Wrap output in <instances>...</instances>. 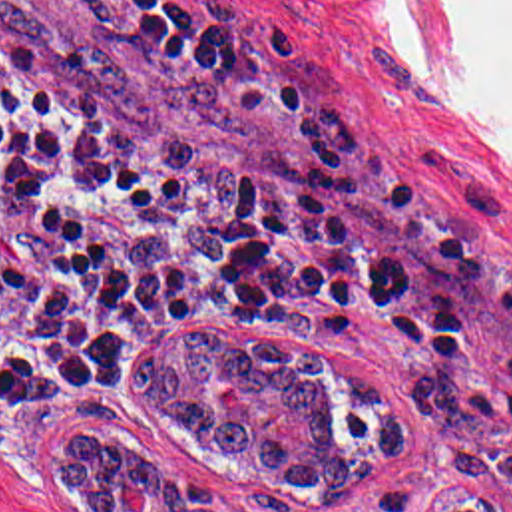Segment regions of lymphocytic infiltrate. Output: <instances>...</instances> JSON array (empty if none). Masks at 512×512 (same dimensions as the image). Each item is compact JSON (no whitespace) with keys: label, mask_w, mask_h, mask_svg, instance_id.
Here are the masks:
<instances>
[{"label":"lymphocytic infiltrate","mask_w":512,"mask_h":512,"mask_svg":"<svg viewBox=\"0 0 512 512\" xmlns=\"http://www.w3.org/2000/svg\"><path fill=\"white\" fill-rule=\"evenodd\" d=\"M127 59L248 99L292 139L318 230L208 185L0 61V422L107 388L147 324H328L385 356L512 322V280L437 240L344 115L198 0H61Z\"/></svg>","instance_id":"f902f5d3"}]
</instances>
